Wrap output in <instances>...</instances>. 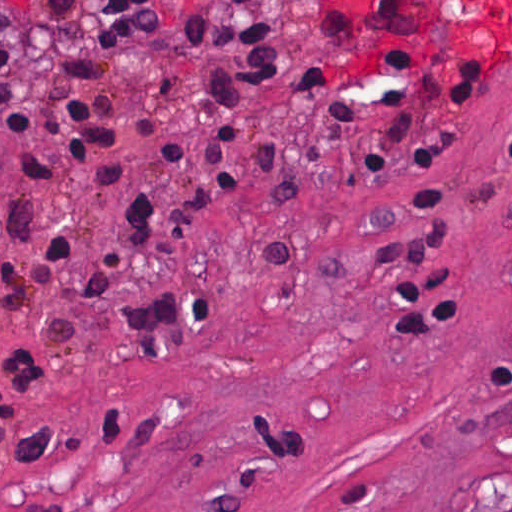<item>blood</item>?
Instances as JSON below:
<instances>
[{
  "label": "blood",
  "mask_w": 512,
  "mask_h": 512,
  "mask_svg": "<svg viewBox=\"0 0 512 512\" xmlns=\"http://www.w3.org/2000/svg\"><path fill=\"white\" fill-rule=\"evenodd\" d=\"M332 1L358 15H373L418 35L461 42H512V0Z\"/></svg>",
  "instance_id": "1"
}]
</instances>
